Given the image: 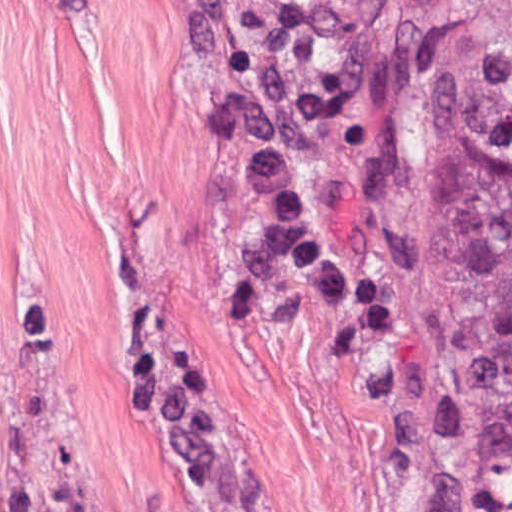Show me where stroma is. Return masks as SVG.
Segmentation results:
<instances>
[{"mask_svg": "<svg viewBox=\"0 0 512 512\" xmlns=\"http://www.w3.org/2000/svg\"><path fill=\"white\" fill-rule=\"evenodd\" d=\"M459 0H0V330L72 512H499L428 24Z\"/></svg>", "mask_w": 512, "mask_h": 512, "instance_id": "stroma-1", "label": "stroma"}]
</instances>
